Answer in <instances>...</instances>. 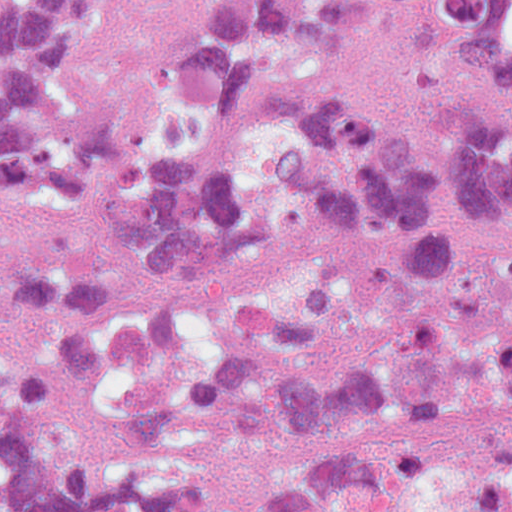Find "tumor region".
Returning <instances> with one entry per match:
<instances>
[{
    "mask_svg": "<svg viewBox=\"0 0 512 512\" xmlns=\"http://www.w3.org/2000/svg\"><path fill=\"white\" fill-rule=\"evenodd\" d=\"M84 0H0V512H512V0H171L69 125Z\"/></svg>",
    "mask_w": 512,
    "mask_h": 512,
    "instance_id": "tumor-region-1",
    "label": "tumor region"
}]
</instances>
